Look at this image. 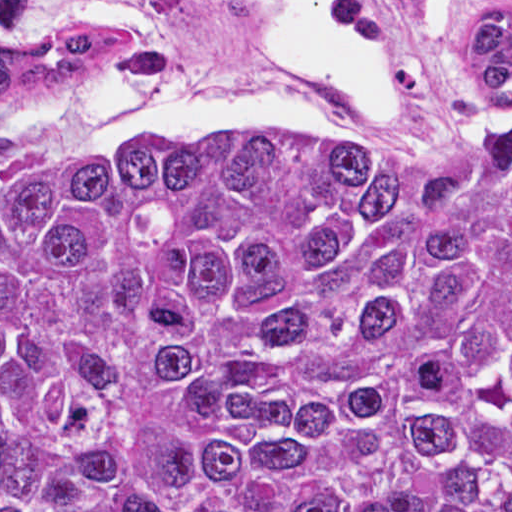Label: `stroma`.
Segmentation results:
<instances>
[{
    "label": "stroma",
    "instance_id": "stroma-1",
    "mask_svg": "<svg viewBox=\"0 0 512 512\" xmlns=\"http://www.w3.org/2000/svg\"><path fill=\"white\" fill-rule=\"evenodd\" d=\"M357 26L384 61L393 83V109L367 104L334 85L300 76V94L317 121L305 128H266L370 146L423 172L421 158L445 98L453 55L450 31L435 0H346ZM78 0H30L22 24L27 41L55 28L119 29L74 9ZM126 31V30H125ZM169 49L164 64L143 77L185 93H224L253 87L259 74V20L243 0H166L160 33L127 31ZM0 49L13 50L0 34ZM122 80L98 76L74 88L0 97V128L17 131L15 156L0 161V181L56 160L103 146L176 142L228 127L193 120H144L127 126L89 123L95 84ZM479 275L512 288V279Z\"/></svg>",
    "mask_w": 512,
    "mask_h": 512
}]
</instances>
